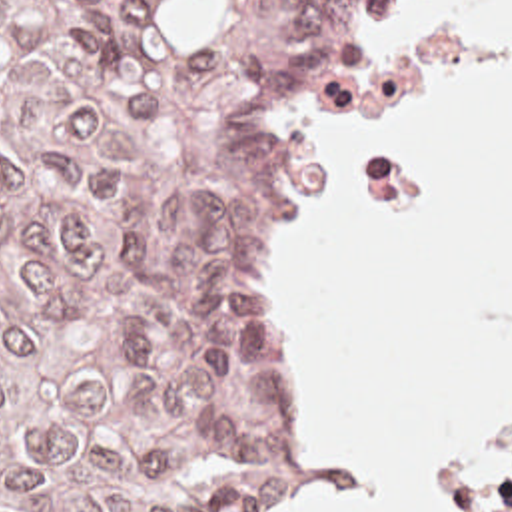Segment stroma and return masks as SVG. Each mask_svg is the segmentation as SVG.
Returning a JSON list of instances; mask_svg holds the SVG:
<instances>
[{"label":"stroma","mask_w":512,"mask_h":512,"mask_svg":"<svg viewBox=\"0 0 512 512\" xmlns=\"http://www.w3.org/2000/svg\"><path fill=\"white\" fill-rule=\"evenodd\" d=\"M396 0H368L362 17L354 29V35L332 75V81L314 109V113L294 129L284 143L282 153V243L286 255V359L290 367L292 387H294V466L280 486V490L260 502L250 504V512H284L282 508L302 496L306 488V470L302 466V444H300V277L304 269V237H306V217L310 211V173L316 149L318 127L326 113L332 109L336 97L346 87L362 49L374 35L382 15L392 9ZM512 442V421L482 442L476 450L468 452L460 460L438 468L440 488L446 486L460 472L484 462L506 444ZM452 512H458L450 506Z\"/></svg>","instance_id":"35a3bbf8"}]
</instances>
